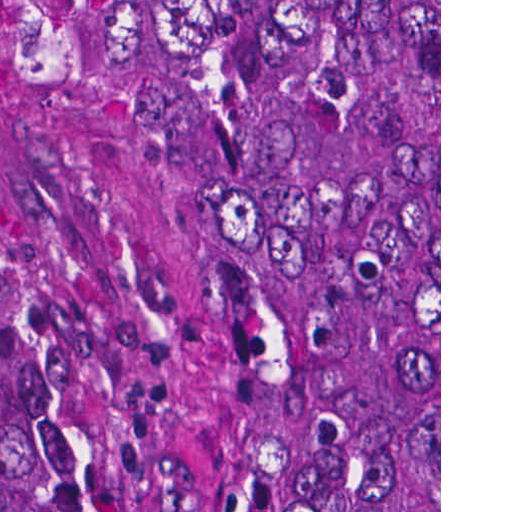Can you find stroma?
I'll return each instance as SVG.
<instances>
[{
  "label": "stroma",
  "instance_id": "1",
  "mask_svg": "<svg viewBox=\"0 0 512 512\" xmlns=\"http://www.w3.org/2000/svg\"><path fill=\"white\" fill-rule=\"evenodd\" d=\"M0 320L136 512H218V302L163 0H0Z\"/></svg>",
  "mask_w": 512,
  "mask_h": 512
}]
</instances>
